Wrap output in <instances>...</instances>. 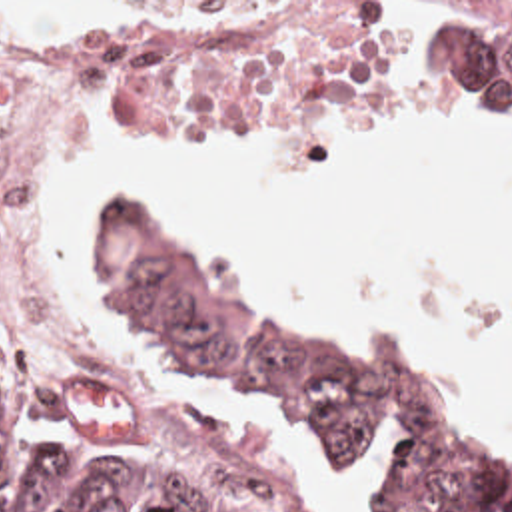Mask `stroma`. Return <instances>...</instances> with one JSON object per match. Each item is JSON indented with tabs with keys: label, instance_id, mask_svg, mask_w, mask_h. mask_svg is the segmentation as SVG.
Returning a JSON list of instances; mask_svg holds the SVG:
<instances>
[{
	"label": "stroma",
	"instance_id": "obj_1",
	"mask_svg": "<svg viewBox=\"0 0 512 512\" xmlns=\"http://www.w3.org/2000/svg\"><path fill=\"white\" fill-rule=\"evenodd\" d=\"M0 2H410V0H0ZM444 16L458 2L438 0ZM396 42V40H394ZM394 50V46H392ZM392 54V52H390ZM390 58V56H388ZM75 96L113 100L142 142L210 140L224 132H282L310 94H172L150 90L111 70H67L37 84L7 148V232L11 254L25 264L23 224L49 182L63 110ZM111 200H134L117 194ZM109 202V200H107ZM0 345L39 353L67 371H103L53 317L1 321Z\"/></svg>",
	"mask_w": 512,
	"mask_h": 512
}]
</instances>
